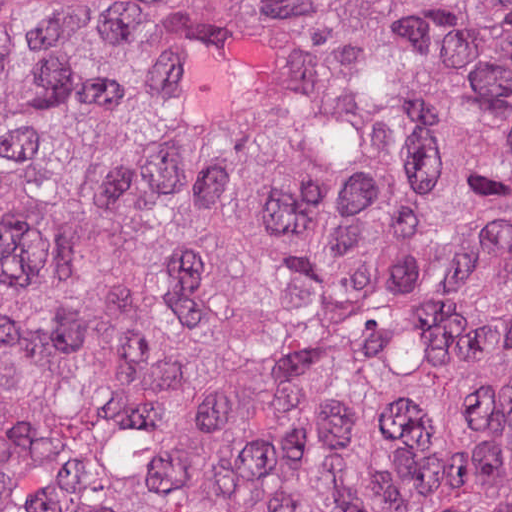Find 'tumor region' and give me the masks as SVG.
I'll list each match as a JSON object with an SVG mask.
<instances>
[{"label": "tumor region", "mask_w": 512, "mask_h": 512, "mask_svg": "<svg viewBox=\"0 0 512 512\" xmlns=\"http://www.w3.org/2000/svg\"><path fill=\"white\" fill-rule=\"evenodd\" d=\"M0 512H512V0H0Z\"/></svg>", "instance_id": "tumor-region-1"}]
</instances>
